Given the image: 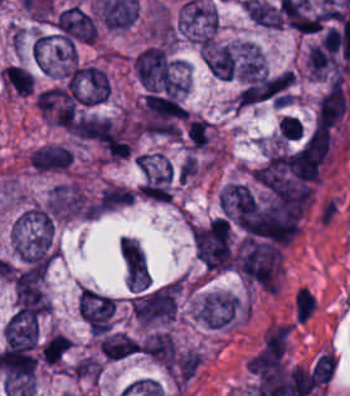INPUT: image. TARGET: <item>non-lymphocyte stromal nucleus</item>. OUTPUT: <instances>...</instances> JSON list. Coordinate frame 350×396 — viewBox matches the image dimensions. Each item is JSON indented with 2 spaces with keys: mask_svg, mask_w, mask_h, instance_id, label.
<instances>
[{
  "mask_svg": "<svg viewBox=\"0 0 350 396\" xmlns=\"http://www.w3.org/2000/svg\"><path fill=\"white\" fill-rule=\"evenodd\" d=\"M293 86L292 70L251 78L238 95V104L280 107L292 99Z\"/></svg>",
  "mask_w": 350,
  "mask_h": 396,
  "instance_id": "1",
  "label": "non-lymphocyte stromal nucleus"
},
{
  "mask_svg": "<svg viewBox=\"0 0 350 396\" xmlns=\"http://www.w3.org/2000/svg\"><path fill=\"white\" fill-rule=\"evenodd\" d=\"M288 335L286 324L267 328L246 363L249 370L264 378L281 367Z\"/></svg>",
  "mask_w": 350,
  "mask_h": 396,
  "instance_id": "2",
  "label": "non-lymphocyte stromal nucleus"
}]
</instances>
